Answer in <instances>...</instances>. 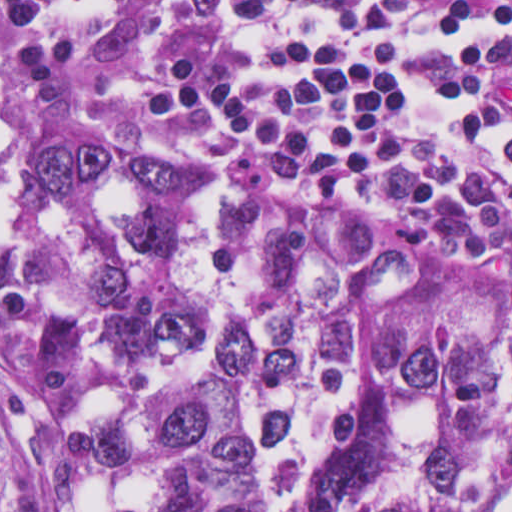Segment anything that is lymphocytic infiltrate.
Listing matches in <instances>:
<instances>
[{
	"label": "lymphocytic infiltrate",
	"instance_id": "lymphocytic-infiltrate-1",
	"mask_svg": "<svg viewBox=\"0 0 512 512\" xmlns=\"http://www.w3.org/2000/svg\"><path fill=\"white\" fill-rule=\"evenodd\" d=\"M98 117L269 192L512 257V0H1Z\"/></svg>",
	"mask_w": 512,
	"mask_h": 512
}]
</instances>
